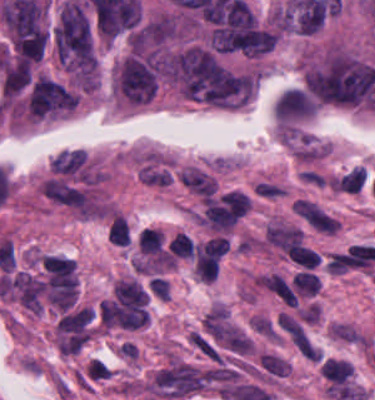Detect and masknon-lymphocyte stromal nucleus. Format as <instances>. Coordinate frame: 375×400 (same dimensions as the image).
<instances>
[{"label":"non-lymphocyte stromal nucleus","instance_id":"obj_6","mask_svg":"<svg viewBox=\"0 0 375 400\" xmlns=\"http://www.w3.org/2000/svg\"><path fill=\"white\" fill-rule=\"evenodd\" d=\"M261 285L285 304L297 306V298L281 274H267L261 278Z\"/></svg>","mask_w":375,"mask_h":400},{"label":"non-lymphocyte stromal nucleus","instance_id":"obj_3","mask_svg":"<svg viewBox=\"0 0 375 400\" xmlns=\"http://www.w3.org/2000/svg\"><path fill=\"white\" fill-rule=\"evenodd\" d=\"M294 210L300 214L315 229L333 233L340 225L338 219L321 209L310 200L297 199Z\"/></svg>","mask_w":375,"mask_h":400},{"label":"non-lymphocyte stromal nucleus","instance_id":"obj_2","mask_svg":"<svg viewBox=\"0 0 375 400\" xmlns=\"http://www.w3.org/2000/svg\"><path fill=\"white\" fill-rule=\"evenodd\" d=\"M10 287L17 299L29 310H43V283L37 278L24 272H17L11 282Z\"/></svg>","mask_w":375,"mask_h":400},{"label":"non-lymphocyte stromal nucleus","instance_id":"obj_5","mask_svg":"<svg viewBox=\"0 0 375 400\" xmlns=\"http://www.w3.org/2000/svg\"><path fill=\"white\" fill-rule=\"evenodd\" d=\"M180 179L192 193L208 199L213 195L216 182L196 167L185 169Z\"/></svg>","mask_w":375,"mask_h":400},{"label":"non-lymphocyte stromal nucleus","instance_id":"obj_1","mask_svg":"<svg viewBox=\"0 0 375 400\" xmlns=\"http://www.w3.org/2000/svg\"><path fill=\"white\" fill-rule=\"evenodd\" d=\"M206 376L189 364L177 363L155 376L156 386L167 396L183 397L201 391Z\"/></svg>","mask_w":375,"mask_h":400},{"label":"non-lymphocyte stromal nucleus","instance_id":"obj_4","mask_svg":"<svg viewBox=\"0 0 375 400\" xmlns=\"http://www.w3.org/2000/svg\"><path fill=\"white\" fill-rule=\"evenodd\" d=\"M266 240L286 254L301 243L302 230L297 227L269 224Z\"/></svg>","mask_w":375,"mask_h":400}]
</instances>
